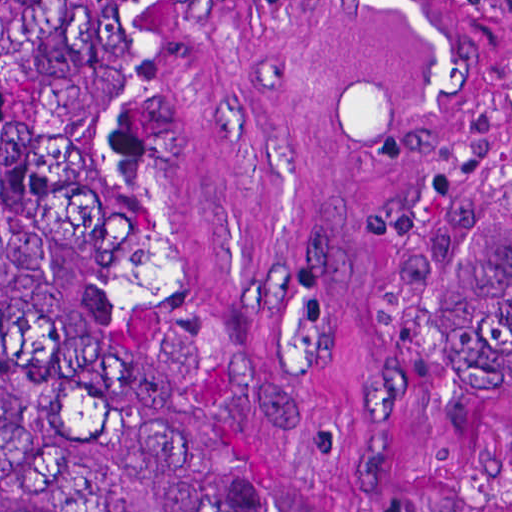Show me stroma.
Here are the masks:
<instances>
[{"mask_svg": "<svg viewBox=\"0 0 512 512\" xmlns=\"http://www.w3.org/2000/svg\"><path fill=\"white\" fill-rule=\"evenodd\" d=\"M512 132V0H192L238 287L361 512H512L436 293L430 142Z\"/></svg>", "mask_w": 512, "mask_h": 512, "instance_id": "obj_1", "label": "stroma"}]
</instances>
